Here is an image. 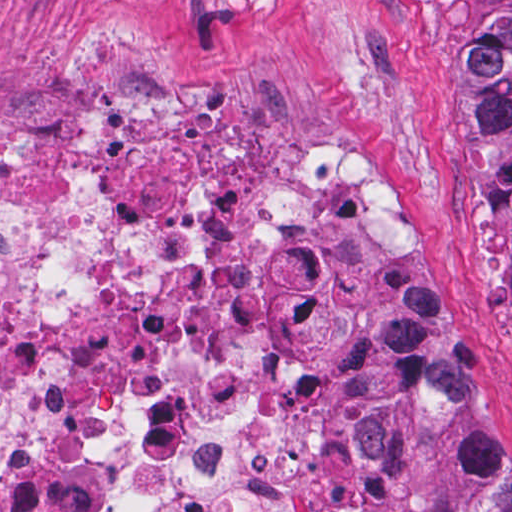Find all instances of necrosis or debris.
Segmentation results:
<instances>
[{
	"instance_id": "4bbe7bcc",
	"label": "necrosis or debris",
	"mask_w": 512,
	"mask_h": 512,
	"mask_svg": "<svg viewBox=\"0 0 512 512\" xmlns=\"http://www.w3.org/2000/svg\"><path fill=\"white\" fill-rule=\"evenodd\" d=\"M0 512H431L374 400L420 223L366 163L252 158L197 98L115 94L74 140L0 146ZM374 296L364 467L278 472L272 348Z\"/></svg>"
}]
</instances>
